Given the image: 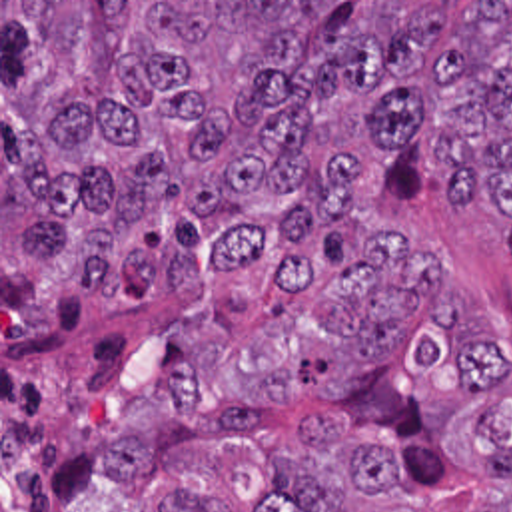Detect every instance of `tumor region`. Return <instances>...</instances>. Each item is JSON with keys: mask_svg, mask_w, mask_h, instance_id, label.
<instances>
[{"mask_svg": "<svg viewBox=\"0 0 512 512\" xmlns=\"http://www.w3.org/2000/svg\"><path fill=\"white\" fill-rule=\"evenodd\" d=\"M2 2V325H30L70 291L142 307L154 287L204 291L355 210L357 154L413 146L445 168L449 200L495 204L512 252V2ZM397 228V226H395ZM399 230V228H397ZM315 297L337 335L315 371L347 389L393 357L445 287V262L407 234ZM411 363L453 359L467 387L499 377L465 293ZM192 371L124 409L114 483H146L176 439H254L256 411L200 413ZM270 455L252 512H345L405 491V467L335 421L303 415ZM467 459L512 483L511 401L467 427ZM150 512H230L218 481L182 467ZM512 512V511H511Z\"/></svg>", "mask_w": 512, "mask_h": 512, "instance_id": "1", "label": "tumor region"}]
</instances>
